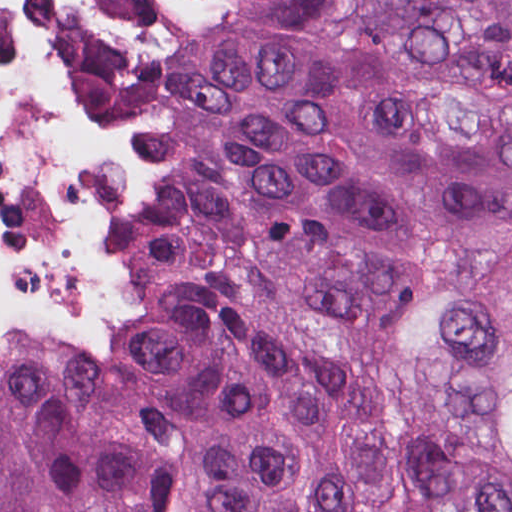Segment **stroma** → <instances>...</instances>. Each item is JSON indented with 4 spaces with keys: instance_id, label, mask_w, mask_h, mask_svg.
<instances>
[{
    "instance_id": "obj_1",
    "label": "stroma",
    "mask_w": 512,
    "mask_h": 512,
    "mask_svg": "<svg viewBox=\"0 0 512 512\" xmlns=\"http://www.w3.org/2000/svg\"><path fill=\"white\" fill-rule=\"evenodd\" d=\"M88 54L110 116L127 144L123 121V0H88ZM162 288L155 265L149 284L131 307Z\"/></svg>"
}]
</instances>
